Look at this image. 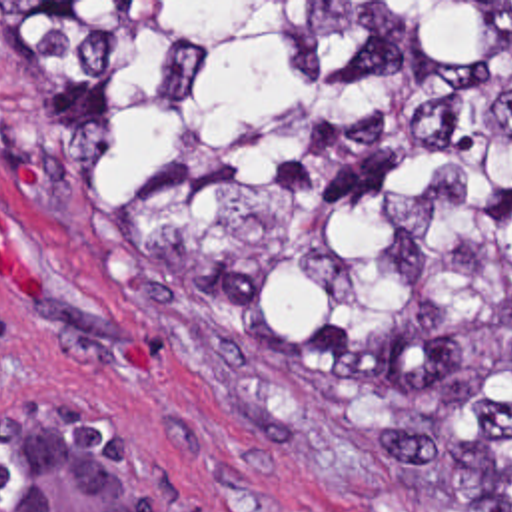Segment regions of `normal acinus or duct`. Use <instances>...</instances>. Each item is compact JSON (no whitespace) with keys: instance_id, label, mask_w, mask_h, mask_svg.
Returning a JSON list of instances; mask_svg holds the SVG:
<instances>
[{"instance_id":"obj_1","label":"normal acinus or duct","mask_w":512,"mask_h":512,"mask_svg":"<svg viewBox=\"0 0 512 512\" xmlns=\"http://www.w3.org/2000/svg\"><path fill=\"white\" fill-rule=\"evenodd\" d=\"M0 512H180L128 423L78 403L0 411Z\"/></svg>"}]
</instances>
